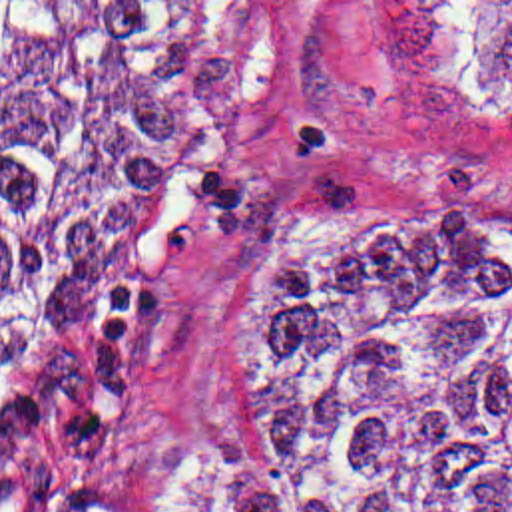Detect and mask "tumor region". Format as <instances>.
Returning a JSON list of instances; mask_svg holds the SVG:
<instances>
[{"instance_id": "obj_1", "label": "tumor region", "mask_w": 512, "mask_h": 512, "mask_svg": "<svg viewBox=\"0 0 512 512\" xmlns=\"http://www.w3.org/2000/svg\"><path fill=\"white\" fill-rule=\"evenodd\" d=\"M512 92V2H450ZM209 125L197 2H0V506L135 339V253ZM255 466H130L110 512H512V197L376 163L293 215L243 329Z\"/></svg>"}]
</instances>
